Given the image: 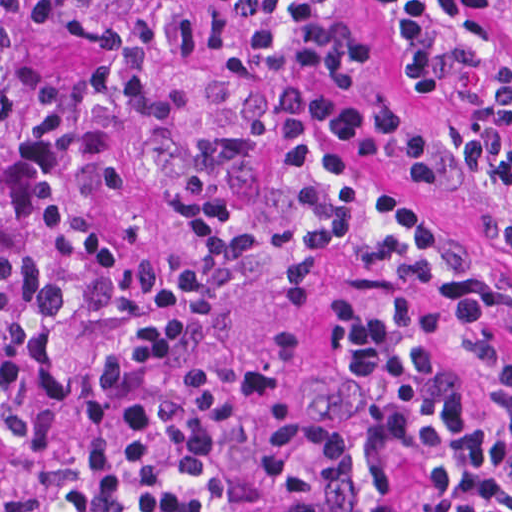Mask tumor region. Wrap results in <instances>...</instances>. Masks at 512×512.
Wrapping results in <instances>:
<instances>
[{
	"instance_id": "e687c5a6",
	"label": "tumor region",
	"mask_w": 512,
	"mask_h": 512,
	"mask_svg": "<svg viewBox=\"0 0 512 512\" xmlns=\"http://www.w3.org/2000/svg\"><path fill=\"white\" fill-rule=\"evenodd\" d=\"M182 0H0V485L72 399L94 222L132 150Z\"/></svg>"
}]
</instances>
